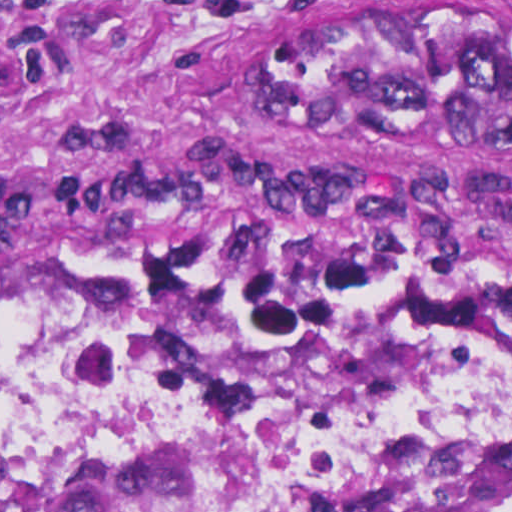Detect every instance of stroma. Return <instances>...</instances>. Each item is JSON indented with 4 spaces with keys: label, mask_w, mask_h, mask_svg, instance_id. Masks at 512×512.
<instances>
[{
    "label": "stroma",
    "mask_w": 512,
    "mask_h": 512,
    "mask_svg": "<svg viewBox=\"0 0 512 512\" xmlns=\"http://www.w3.org/2000/svg\"><path fill=\"white\" fill-rule=\"evenodd\" d=\"M353 1L0 0V243L512 322V163L373 153L268 105V63Z\"/></svg>",
    "instance_id": "obj_1"
}]
</instances>
